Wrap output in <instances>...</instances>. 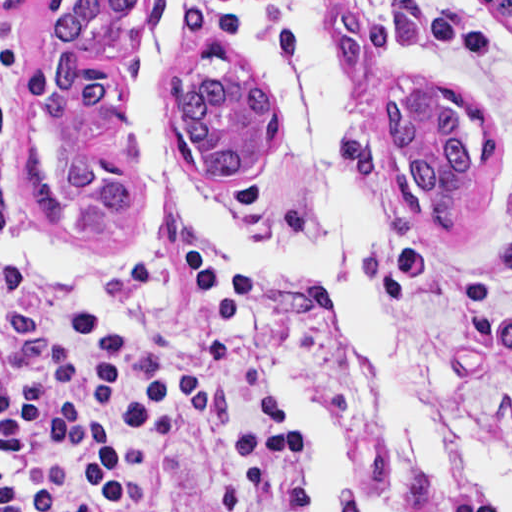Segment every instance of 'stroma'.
Instances as JSON below:
<instances>
[{
  "label": "stroma",
  "instance_id": "1",
  "mask_svg": "<svg viewBox=\"0 0 512 512\" xmlns=\"http://www.w3.org/2000/svg\"><path fill=\"white\" fill-rule=\"evenodd\" d=\"M59 1H153V13L142 24L74 56L109 62L122 81L76 161L96 181L139 194L152 207L153 235L137 249H110L92 241L59 203L45 158L46 94L29 73L33 29ZM397 1L429 18L465 21L481 32L486 49L406 51L381 64L366 87H355L338 74L345 105L338 153L370 202L364 266L399 344L459 374L450 412L461 436L480 448L512 453V29L488 6V1L512 0H326V34L335 58L337 10L356 8L371 18H391ZM169 2L0 0V31L19 48L9 134L10 194L35 270L49 285H77L94 276L131 280L172 249L239 253L172 214L148 182L133 135L132 75ZM174 32L179 40L169 69L161 72L162 94L171 78L200 69L197 54L207 42H226L252 58L256 70L251 52L226 24L225 0H191ZM406 77L425 79L472 103L498 134L496 178L460 232L423 228L394 187L393 143L381 113L389 84ZM162 118L165 127L163 108ZM174 153L190 188L222 217L245 226L295 227L300 157L283 115L277 147L240 179L212 178ZM254 360L271 381L255 349ZM446 511L495 512L487 501L462 493L446 498Z\"/></svg>",
  "mask_w": 512,
  "mask_h": 512
}]
</instances>
